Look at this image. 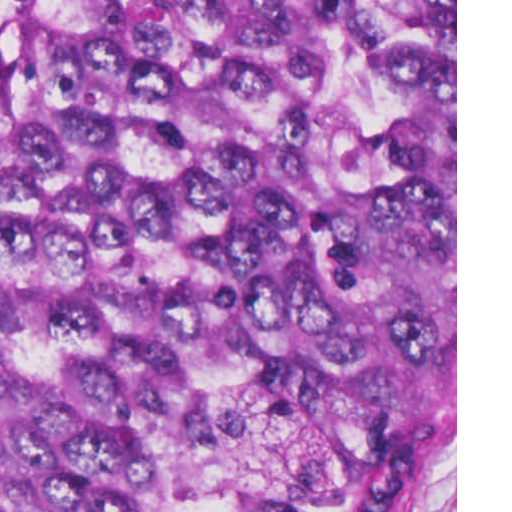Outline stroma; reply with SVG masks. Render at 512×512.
Listing matches in <instances>:
<instances>
[{
    "mask_svg": "<svg viewBox=\"0 0 512 512\" xmlns=\"http://www.w3.org/2000/svg\"><path fill=\"white\" fill-rule=\"evenodd\" d=\"M377 512H457V0H455V461L393 489Z\"/></svg>",
    "mask_w": 512,
    "mask_h": 512,
    "instance_id": "stroma-1",
    "label": "stroma"
}]
</instances>
